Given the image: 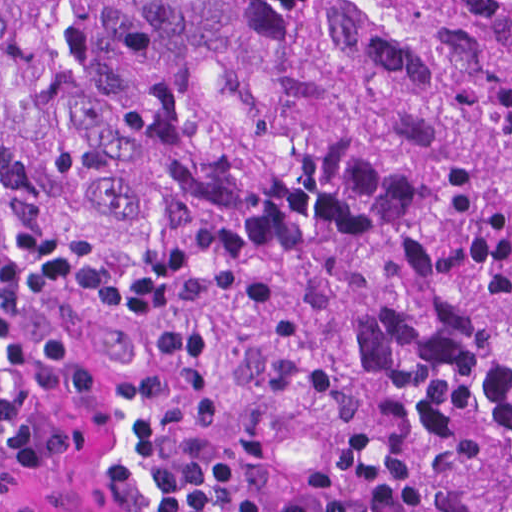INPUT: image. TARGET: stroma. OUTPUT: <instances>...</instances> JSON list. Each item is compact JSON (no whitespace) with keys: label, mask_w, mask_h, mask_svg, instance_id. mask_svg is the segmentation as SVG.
<instances>
[{"label":"stroma","mask_w":512,"mask_h":512,"mask_svg":"<svg viewBox=\"0 0 512 512\" xmlns=\"http://www.w3.org/2000/svg\"><path fill=\"white\" fill-rule=\"evenodd\" d=\"M34 162L0 144V512H150L180 457L214 454L250 502L403 496L420 512H512V305L494 404L472 450L418 479H312L136 411L72 392L31 309Z\"/></svg>","instance_id":"35a3bbf8"}]
</instances>
